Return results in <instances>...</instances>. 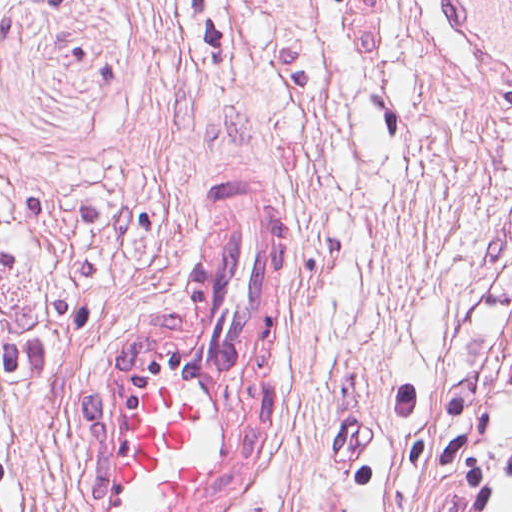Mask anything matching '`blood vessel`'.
<instances>
[{"instance_id": "1", "label": "blood vessel", "mask_w": 512, "mask_h": 512, "mask_svg": "<svg viewBox=\"0 0 512 512\" xmlns=\"http://www.w3.org/2000/svg\"><path fill=\"white\" fill-rule=\"evenodd\" d=\"M512 101V0H435ZM287 182L222 181L171 283L77 394L80 512H224L259 478L282 372Z\"/></svg>"}]
</instances>
